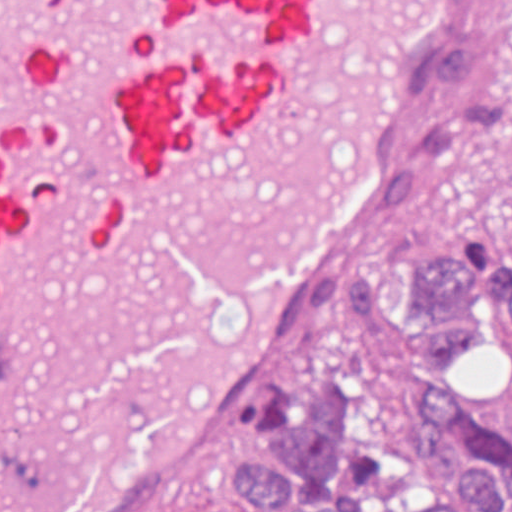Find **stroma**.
Listing matches in <instances>:
<instances>
[{
    "label": "stroma",
    "instance_id": "obj_1",
    "mask_svg": "<svg viewBox=\"0 0 512 512\" xmlns=\"http://www.w3.org/2000/svg\"><path fill=\"white\" fill-rule=\"evenodd\" d=\"M472 1L464 2L444 40L462 29ZM441 95L435 58L427 84V140ZM415 242H473L477 265L499 286L512 284L501 195L484 168L462 163L429 207L407 208L283 362L251 417L152 512H172L176 493L204 476L227 498L229 512H265L220 477V448L247 437H277L296 385L315 359L345 376L355 404L382 431H410L421 403L450 391L472 336H494L512 308L498 299L474 310H437L405 299ZM489 397L512 407V329L494 337Z\"/></svg>",
    "mask_w": 512,
    "mask_h": 512
}]
</instances>
